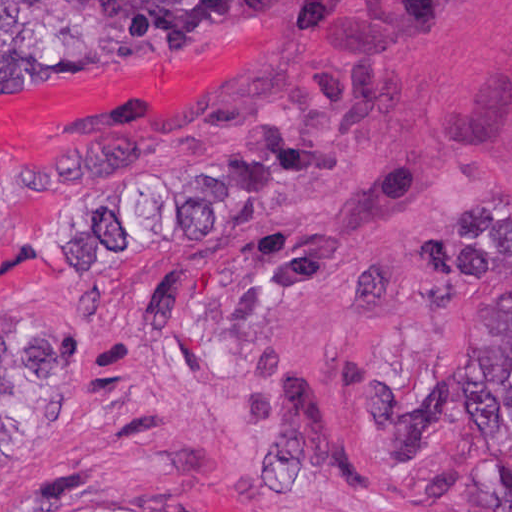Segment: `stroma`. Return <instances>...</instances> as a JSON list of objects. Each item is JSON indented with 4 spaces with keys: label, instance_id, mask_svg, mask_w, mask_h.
<instances>
[{
    "label": "stroma",
    "instance_id": "1",
    "mask_svg": "<svg viewBox=\"0 0 512 512\" xmlns=\"http://www.w3.org/2000/svg\"><path fill=\"white\" fill-rule=\"evenodd\" d=\"M0 99V331L75 401L0 512H485L512 0H291Z\"/></svg>",
    "mask_w": 512,
    "mask_h": 512
}]
</instances>
